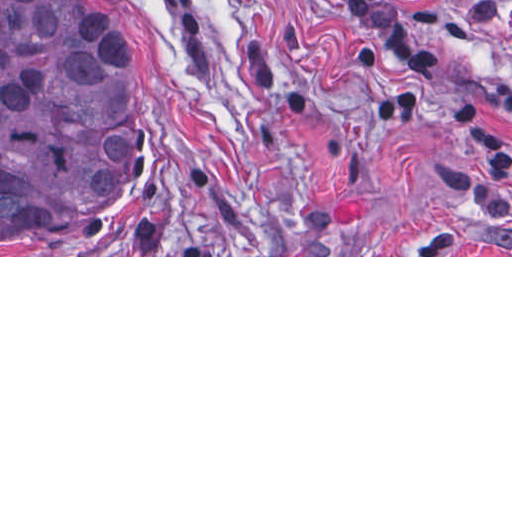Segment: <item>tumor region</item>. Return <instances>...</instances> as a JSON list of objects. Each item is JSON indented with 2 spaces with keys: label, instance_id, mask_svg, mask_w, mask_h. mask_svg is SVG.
Segmentation results:
<instances>
[{
  "label": "tumor region",
  "instance_id": "tumor-region-1",
  "mask_svg": "<svg viewBox=\"0 0 512 512\" xmlns=\"http://www.w3.org/2000/svg\"><path fill=\"white\" fill-rule=\"evenodd\" d=\"M136 65L99 0H0V250H49L139 216Z\"/></svg>",
  "mask_w": 512,
  "mask_h": 512
}]
</instances>
